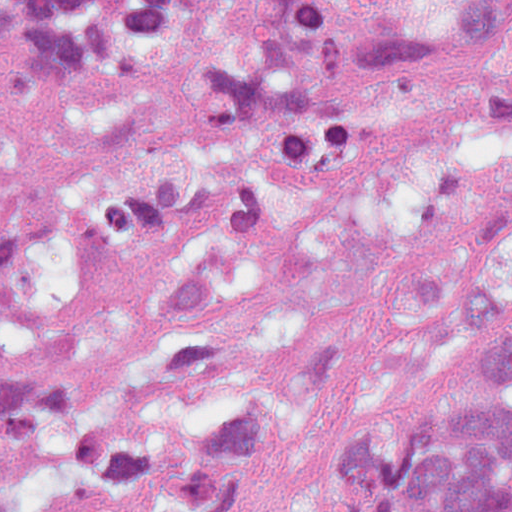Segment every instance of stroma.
<instances>
[{"label": "stroma", "mask_w": 512, "mask_h": 512, "mask_svg": "<svg viewBox=\"0 0 512 512\" xmlns=\"http://www.w3.org/2000/svg\"><path fill=\"white\" fill-rule=\"evenodd\" d=\"M19 26H0V221H27L25 252L0 260V369L40 365L80 383L119 343L157 285L210 249L295 234L427 243L512 276V145L480 137L450 98L413 84L370 91L367 129L328 179L302 188L229 184L167 246L104 245L72 212L80 153L68 130L132 111L140 91L56 75L19 99L4 87ZM487 339L429 381H370L340 396L320 443L268 462L250 512H331L345 446L375 414L492 398Z\"/></svg>", "instance_id": "obj_1"}]
</instances>
